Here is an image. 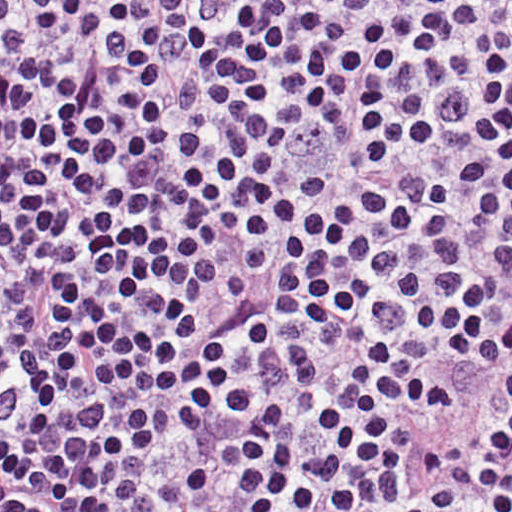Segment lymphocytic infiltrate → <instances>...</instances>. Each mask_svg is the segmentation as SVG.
Wrapping results in <instances>:
<instances>
[{"label":"lymphocytic infiltrate","instance_id":"lymphocytic-infiltrate-1","mask_svg":"<svg viewBox=\"0 0 512 512\" xmlns=\"http://www.w3.org/2000/svg\"><path fill=\"white\" fill-rule=\"evenodd\" d=\"M1 512H512V0H1Z\"/></svg>","mask_w":512,"mask_h":512}]
</instances>
